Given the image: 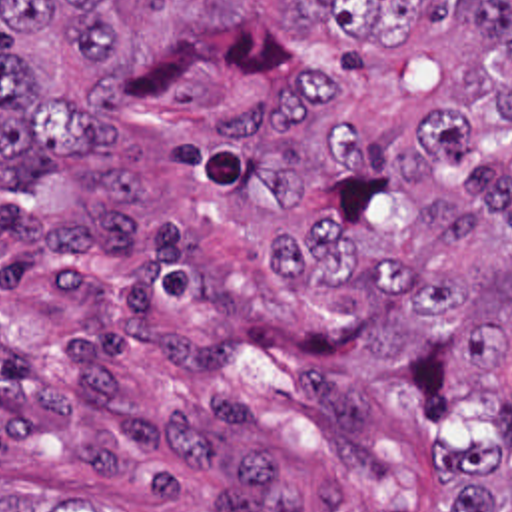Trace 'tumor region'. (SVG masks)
Returning a JSON list of instances; mask_svg holds the SVG:
<instances>
[{
    "label": "tumor region",
    "mask_w": 512,
    "mask_h": 512,
    "mask_svg": "<svg viewBox=\"0 0 512 512\" xmlns=\"http://www.w3.org/2000/svg\"><path fill=\"white\" fill-rule=\"evenodd\" d=\"M193 104L169 164L247 204L294 294L364 284L446 320L494 391L486 443L436 437L452 512H512V0H0L3 186L115 156L119 102ZM0 512H103L51 469Z\"/></svg>",
    "instance_id": "e687c5a6"
}]
</instances>
